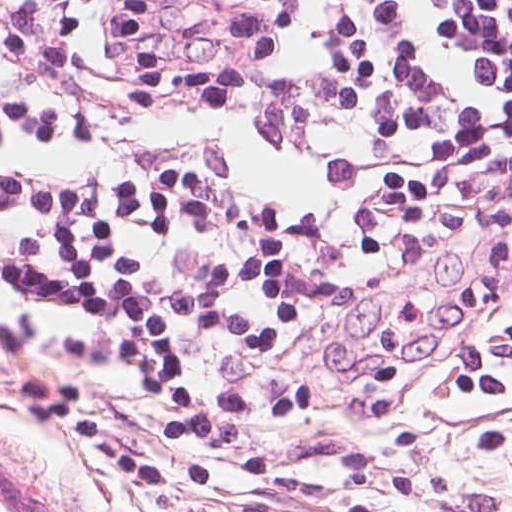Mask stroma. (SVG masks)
Returning a JSON list of instances; mask_svg holds the SVG:
<instances>
[{"label":"stroma","mask_w":512,"mask_h":512,"mask_svg":"<svg viewBox=\"0 0 512 512\" xmlns=\"http://www.w3.org/2000/svg\"><path fill=\"white\" fill-rule=\"evenodd\" d=\"M164 490L264 512H512V210L402 227L299 291L256 427Z\"/></svg>","instance_id":"35a3bbf8"}]
</instances>
